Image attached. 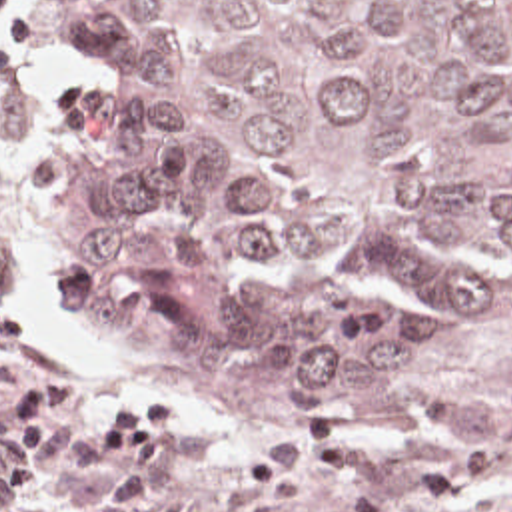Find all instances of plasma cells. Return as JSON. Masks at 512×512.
Returning a JSON list of instances; mask_svg holds the SVG:
<instances>
[{
	"label": "plasma cells",
	"instance_id": "9512152a",
	"mask_svg": "<svg viewBox=\"0 0 512 512\" xmlns=\"http://www.w3.org/2000/svg\"><path fill=\"white\" fill-rule=\"evenodd\" d=\"M457 450L402 454L340 424L274 436L222 492L226 512H270L320 482L344 488V512H435L485 484L499 460L471 436Z\"/></svg>",
	"mask_w": 512,
	"mask_h": 512
}]
</instances>
